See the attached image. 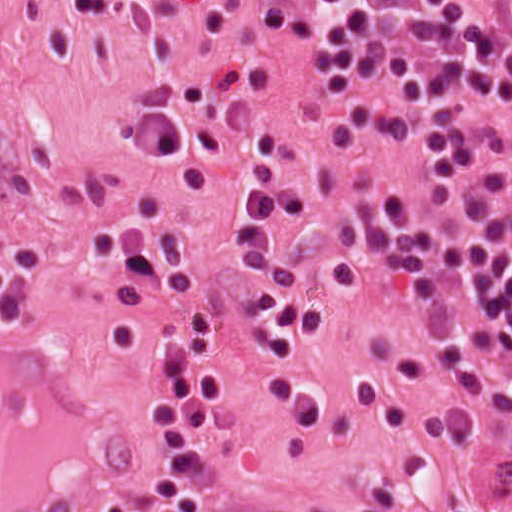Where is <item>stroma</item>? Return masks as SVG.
Returning <instances> with one entry per match:
<instances>
[{
    "instance_id": "stroma-1",
    "label": "stroma",
    "mask_w": 512,
    "mask_h": 512,
    "mask_svg": "<svg viewBox=\"0 0 512 512\" xmlns=\"http://www.w3.org/2000/svg\"><path fill=\"white\" fill-rule=\"evenodd\" d=\"M458 1L492 25L493 0ZM62 2L0 0V512H178L147 398L184 317L128 279L131 246L155 238H178L218 316L208 512H358L381 487L394 512H512V438L477 442L384 286L415 161L341 116L312 0H135L109 19ZM248 177H271L281 254L324 306L308 443L259 378V275L231 246Z\"/></svg>"
}]
</instances>
